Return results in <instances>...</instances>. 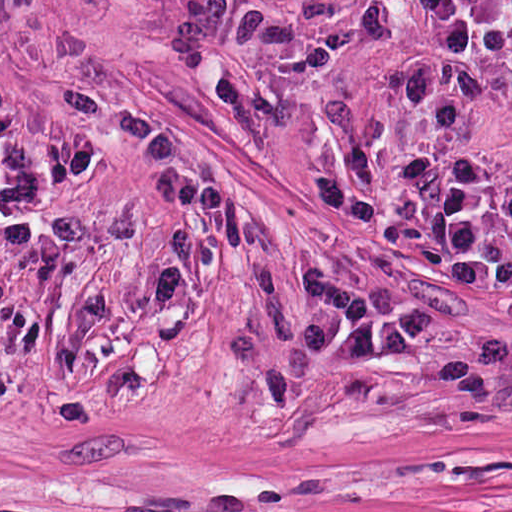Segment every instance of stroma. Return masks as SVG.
Returning <instances> with one entry per match:
<instances>
[{
    "label": "stroma",
    "instance_id": "1",
    "mask_svg": "<svg viewBox=\"0 0 512 512\" xmlns=\"http://www.w3.org/2000/svg\"><path fill=\"white\" fill-rule=\"evenodd\" d=\"M51 512H512V19L217 0Z\"/></svg>",
    "mask_w": 512,
    "mask_h": 512
}]
</instances>
